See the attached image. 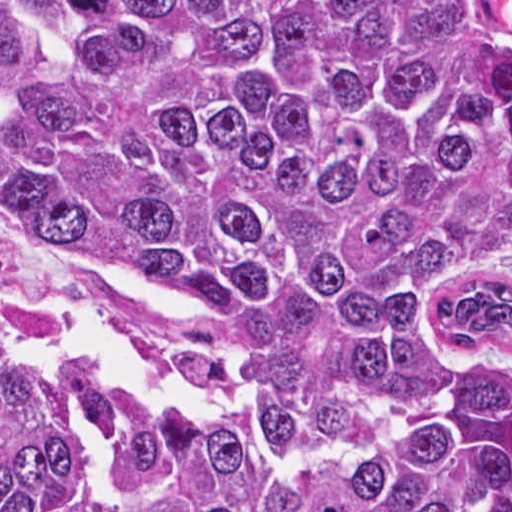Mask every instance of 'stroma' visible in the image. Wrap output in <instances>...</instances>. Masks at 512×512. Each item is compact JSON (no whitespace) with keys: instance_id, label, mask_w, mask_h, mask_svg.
<instances>
[{"instance_id":"stroma-1","label":"stroma","mask_w":512,"mask_h":512,"mask_svg":"<svg viewBox=\"0 0 512 512\" xmlns=\"http://www.w3.org/2000/svg\"><path fill=\"white\" fill-rule=\"evenodd\" d=\"M0 1H489L498 41L512 73V0H0ZM432 337L446 353L512 358V251L487 262L451 293Z\"/></svg>"}]
</instances>
